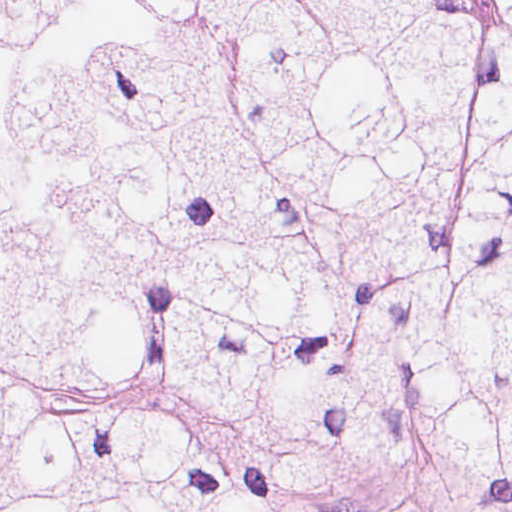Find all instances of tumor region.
I'll list each match as a JSON object with an SVG mask.
<instances>
[{
    "mask_svg": "<svg viewBox=\"0 0 512 512\" xmlns=\"http://www.w3.org/2000/svg\"><path fill=\"white\" fill-rule=\"evenodd\" d=\"M512 512V1H0V512Z\"/></svg>",
    "mask_w": 512,
    "mask_h": 512,
    "instance_id": "obj_1",
    "label": "tumor region"
}]
</instances>
